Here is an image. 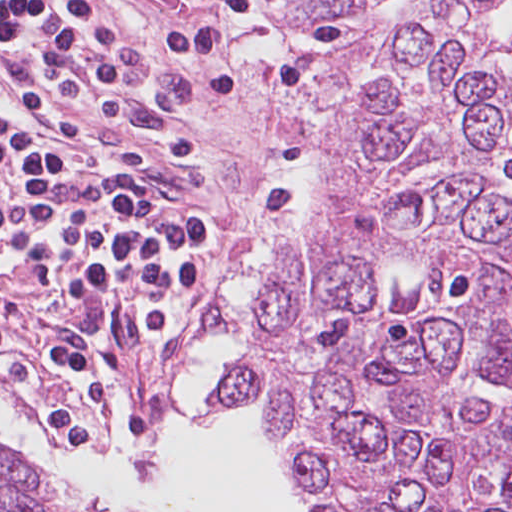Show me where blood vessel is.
Here are the masks:
<instances>
[{"instance_id":"obj_1","label":"blood vessel","mask_w":512,"mask_h":512,"mask_svg":"<svg viewBox=\"0 0 512 512\" xmlns=\"http://www.w3.org/2000/svg\"><path fill=\"white\" fill-rule=\"evenodd\" d=\"M0 142L40 157H100V145L0 55Z\"/></svg>"}]
</instances>
